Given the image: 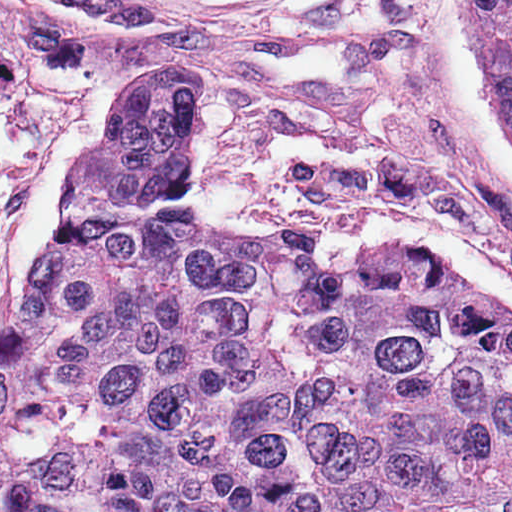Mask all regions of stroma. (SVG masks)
Wrapping results in <instances>:
<instances>
[{
  "mask_svg": "<svg viewBox=\"0 0 512 512\" xmlns=\"http://www.w3.org/2000/svg\"><path fill=\"white\" fill-rule=\"evenodd\" d=\"M154 63L211 94L183 149L210 221L314 248L393 209L512 279V144L464 53V0H0V333L28 312L24 272L79 161L111 135L115 86Z\"/></svg>",
  "mask_w": 512,
  "mask_h": 512,
  "instance_id": "obj_1",
  "label": "stroma"
}]
</instances>
